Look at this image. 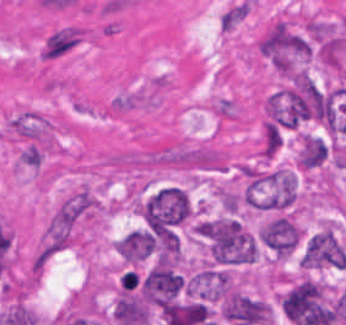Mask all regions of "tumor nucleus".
Returning <instances> with one entry per match:
<instances>
[{
    "label": "tumor nucleus",
    "mask_w": 346,
    "mask_h": 325,
    "mask_svg": "<svg viewBox=\"0 0 346 325\" xmlns=\"http://www.w3.org/2000/svg\"><path fill=\"white\" fill-rule=\"evenodd\" d=\"M257 51L279 73H290L308 54L306 38L281 19H274L258 40Z\"/></svg>",
    "instance_id": "1"
},
{
    "label": "tumor nucleus",
    "mask_w": 346,
    "mask_h": 325,
    "mask_svg": "<svg viewBox=\"0 0 346 325\" xmlns=\"http://www.w3.org/2000/svg\"><path fill=\"white\" fill-rule=\"evenodd\" d=\"M147 226L160 229L177 224L187 216V195L177 188L159 189L142 205Z\"/></svg>",
    "instance_id": "2"
},
{
    "label": "tumor nucleus",
    "mask_w": 346,
    "mask_h": 325,
    "mask_svg": "<svg viewBox=\"0 0 346 325\" xmlns=\"http://www.w3.org/2000/svg\"><path fill=\"white\" fill-rule=\"evenodd\" d=\"M305 269L340 268L346 265V252L332 228H325L309 237L301 255Z\"/></svg>",
    "instance_id": "3"
},
{
    "label": "tumor nucleus",
    "mask_w": 346,
    "mask_h": 325,
    "mask_svg": "<svg viewBox=\"0 0 346 325\" xmlns=\"http://www.w3.org/2000/svg\"><path fill=\"white\" fill-rule=\"evenodd\" d=\"M269 317L266 301L234 290L225 297L224 318L234 325L267 323Z\"/></svg>",
    "instance_id": "4"
},
{
    "label": "tumor nucleus",
    "mask_w": 346,
    "mask_h": 325,
    "mask_svg": "<svg viewBox=\"0 0 346 325\" xmlns=\"http://www.w3.org/2000/svg\"><path fill=\"white\" fill-rule=\"evenodd\" d=\"M299 243V225L291 213L272 216L268 220L267 248L272 256L285 258Z\"/></svg>",
    "instance_id": "5"
}]
</instances>
